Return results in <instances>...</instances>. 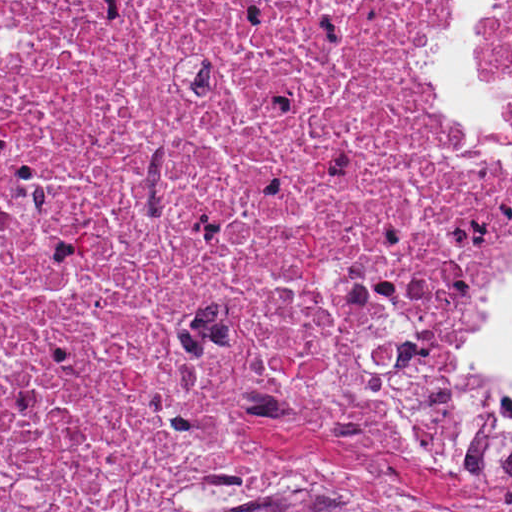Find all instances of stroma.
<instances>
[{
  "label": "stroma",
  "mask_w": 512,
  "mask_h": 512,
  "mask_svg": "<svg viewBox=\"0 0 512 512\" xmlns=\"http://www.w3.org/2000/svg\"><path fill=\"white\" fill-rule=\"evenodd\" d=\"M429 60V41H427ZM496 71L512 86L507 51L496 48ZM486 318L475 331L481 330ZM472 338V340H473ZM0 512H1V0H0ZM347 512H512V488L449 484L419 462L381 454L356 504Z\"/></svg>",
  "instance_id": "35a3bbf8"
}]
</instances>
